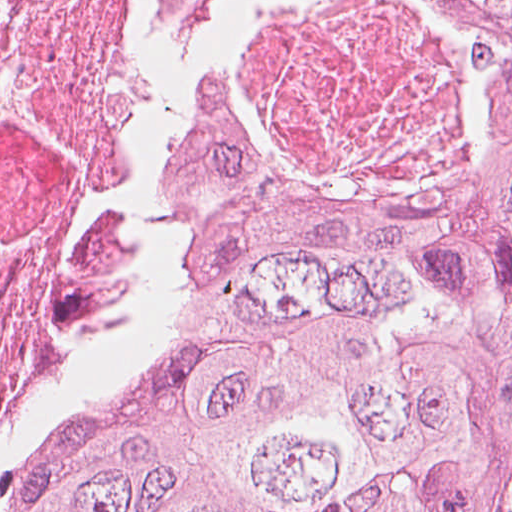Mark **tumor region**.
Listing matches in <instances>:
<instances>
[{
	"label": "tumor region",
	"mask_w": 512,
	"mask_h": 512,
	"mask_svg": "<svg viewBox=\"0 0 512 512\" xmlns=\"http://www.w3.org/2000/svg\"><path fill=\"white\" fill-rule=\"evenodd\" d=\"M139 0L162 77L164 278L0 482V512H500L512 452V0H419L477 127L413 209L261 142L231 85L257 13ZM240 107H239V106Z\"/></svg>",
	"instance_id": "tumor-region-1"
}]
</instances>
